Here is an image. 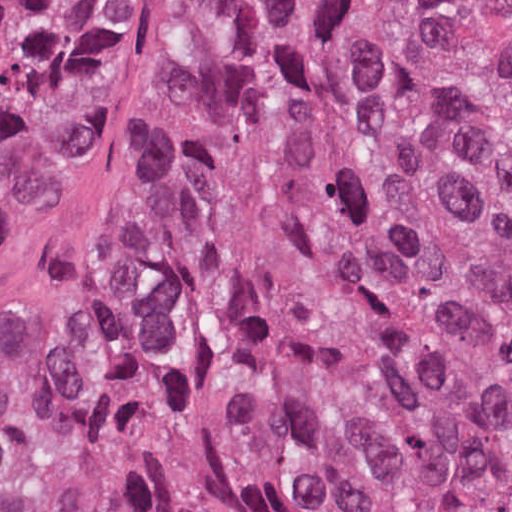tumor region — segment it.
Segmentation results:
<instances>
[{
    "instance_id": "tumor-region-1",
    "label": "tumor region",
    "mask_w": 512,
    "mask_h": 512,
    "mask_svg": "<svg viewBox=\"0 0 512 512\" xmlns=\"http://www.w3.org/2000/svg\"><path fill=\"white\" fill-rule=\"evenodd\" d=\"M108 5L0 0V207ZM29 489L97 512H512V0L199 1Z\"/></svg>"
}]
</instances>
